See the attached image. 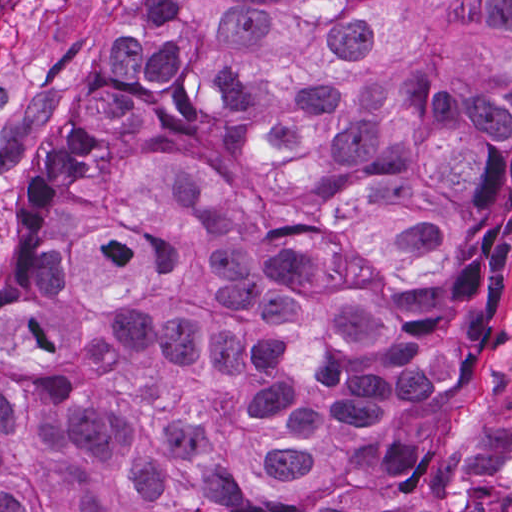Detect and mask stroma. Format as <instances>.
Masks as SVG:
<instances>
[{
  "instance_id": "35a3bbf8",
  "label": "stroma",
  "mask_w": 512,
  "mask_h": 512,
  "mask_svg": "<svg viewBox=\"0 0 512 512\" xmlns=\"http://www.w3.org/2000/svg\"><path fill=\"white\" fill-rule=\"evenodd\" d=\"M149 0H12L0 13V258L30 190L31 166L69 139L110 32ZM489 254L450 275L411 352L431 390L379 423L378 444L413 461L412 484L382 512H414L426 477L435 401L458 330L493 288L507 302L485 345L452 443L436 459V485L419 512H512V225Z\"/></svg>"
}]
</instances>
